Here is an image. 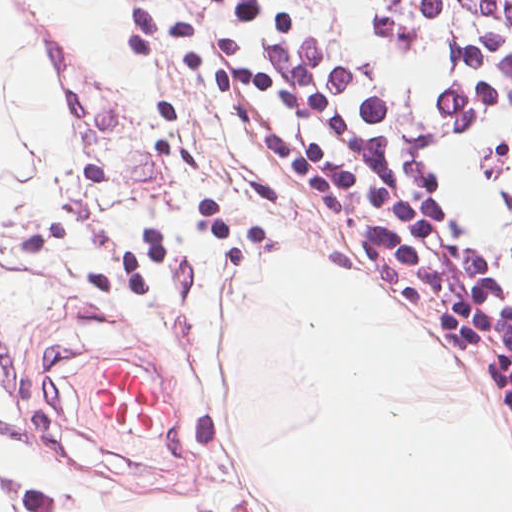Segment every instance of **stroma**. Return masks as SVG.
<instances>
[{
    "label": "stroma",
    "instance_id": "obj_1",
    "mask_svg": "<svg viewBox=\"0 0 512 512\" xmlns=\"http://www.w3.org/2000/svg\"><path fill=\"white\" fill-rule=\"evenodd\" d=\"M8 1L10 34L24 27L60 83L62 119L43 212L0 224V496L13 512H116L164 494L193 512H275L216 394L250 276L285 247L407 305L304 213L149 0H118L146 70L137 95L116 91L35 0ZM423 320L512 446L497 378ZM115 359L166 377L159 444L89 413Z\"/></svg>",
    "mask_w": 512,
    "mask_h": 512
}]
</instances>
